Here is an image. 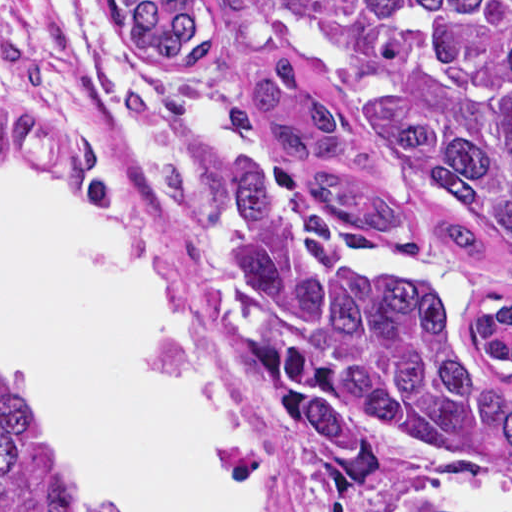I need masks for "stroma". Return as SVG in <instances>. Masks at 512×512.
Returning a JSON list of instances; mask_svg holds the SVG:
<instances>
[{"instance_id":"stroma-1","label":"stroma","mask_w":512,"mask_h":512,"mask_svg":"<svg viewBox=\"0 0 512 512\" xmlns=\"http://www.w3.org/2000/svg\"><path fill=\"white\" fill-rule=\"evenodd\" d=\"M211 2L222 56L208 82L185 83L127 46L115 0H0V163L65 183L92 220L180 291L228 440L273 512H400L403 497L512 493L510 468L428 453L397 436L380 492L337 494L276 429L252 374L256 333L222 267L247 166L300 171L252 96L259 67L290 59L313 89L327 77L360 168L398 233L393 247L359 229L347 233L350 245L389 272L436 276L474 363L511 392L512 370L491 364L475 321L512 302V259L493 240L491 261L444 243L448 219L393 184L365 148L334 61L269 26L247 0Z\"/></svg>"}]
</instances>
